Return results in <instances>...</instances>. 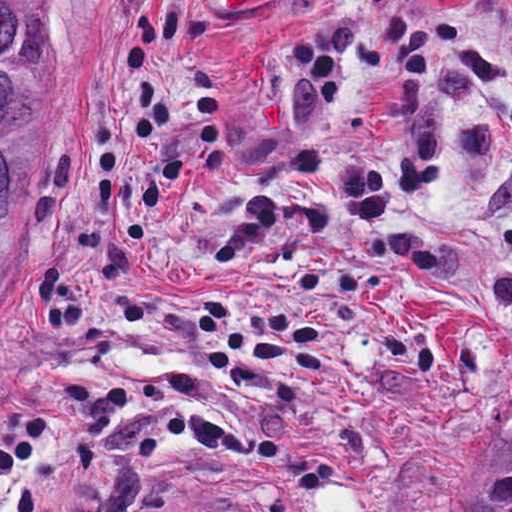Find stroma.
<instances>
[{
  "mask_svg": "<svg viewBox=\"0 0 512 512\" xmlns=\"http://www.w3.org/2000/svg\"><path fill=\"white\" fill-rule=\"evenodd\" d=\"M42 5L0 416L53 424L0 474V512H461L512 404V0ZM175 5L162 82L216 75L222 171L185 116L157 147L130 134L132 27ZM300 36L335 48V111ZM99 121L118 132L104 211ZM351 166L390 187L383 219L334 190ZM249 192L277 223L252 265L217 273L209 250Z\"/></svg>",
  "mask_w": 512,
  "mask_h": 512,
  "instance_id": "stroma-1",
  "label": "stroma"
}]
</instances>
